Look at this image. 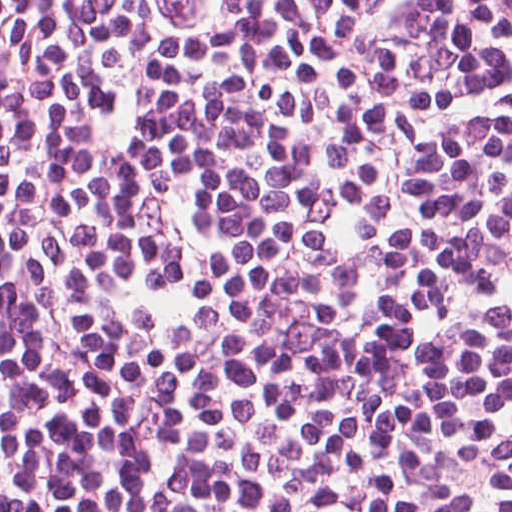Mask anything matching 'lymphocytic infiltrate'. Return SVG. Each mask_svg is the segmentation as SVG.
<instances>
[{
	"instance_id": "lymphocytic-infiltrate-1",
	"label": "lymphocytic infiltrate",
	"mask_w": 512,
	"mask_h": 512,
	"mask_svg": "<svg viewBox=\"0 0 512 512\" xmlns=\"http://www.w3.org/2000/svg\"><path fill=\"white\" fill-rule=\"evenodd\" d=\"M0 512H512V0H0Z\"/></svg>"
}]
</instances>
